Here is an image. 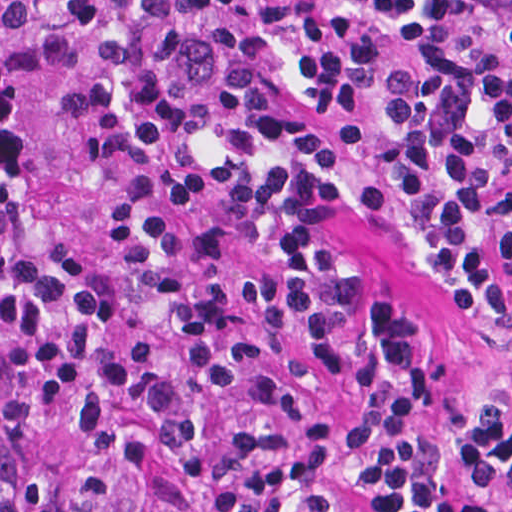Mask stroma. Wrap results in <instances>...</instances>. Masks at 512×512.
<instances>
[{
  "label": "stroma",
  "instance_id": "obj_1",
  "mask_svg": "<svg viewBox=\"0 0 512 512\" xmlns=\"http://www.w3.org/2000/svg\"><path fill=\"white\" fill-rule=\"evenodd\" d=\"M324 242L353 281L347 316L331 360L318 367L288 348L265 354V375L276 401L300 425H335L353 416L376 361L379 302H394L444 370L450 399L447 450L480 511L512 512V486L477 450L479 398L496 366L485 342L443 306L412 257L370 210L352 203L331 207ZM340 496L345 512H378L358 482L340 477Z\"/></svg>",
  "mask_w": 512,
  "mask_h": 512
}]
</instances>
